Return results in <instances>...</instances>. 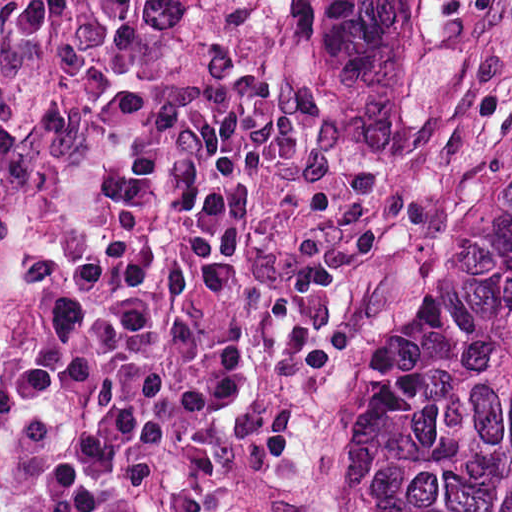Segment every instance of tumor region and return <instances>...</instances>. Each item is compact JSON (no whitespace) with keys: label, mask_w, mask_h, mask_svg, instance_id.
<instances>
[{"label":"tumor region","mask_w":512,"mask_h":512,"mask_svg":"<svg viewBox=\"0 0 512 512\" xmlns=\"http://www.w3.org/2000/svg\"><path fill=\"white\" fill-rule=\"evenodd\" d=\"M318 86L376 131L457 108L492 78L512 0H285ZM358 512H512V186L411 398L356 459Z\"/></svg>","instance_id":"e687c5a6"}]
</instances>
